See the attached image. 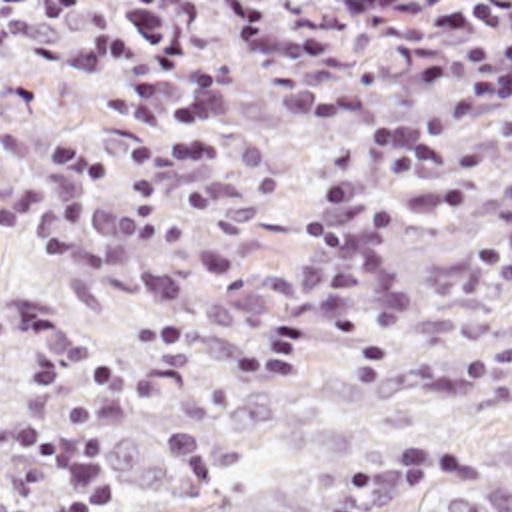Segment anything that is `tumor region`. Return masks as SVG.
<instances>
[{"label":"tumor region","instance_id":"e687c5a6","mask_svg":"<svg viewBox=\"0 0 512 512\" xmlns=\"http://www.w3.org/2000/svg\"><path fill=\"white\" fill-rule=\"evenodd\" d=\"M87 435L103 512H512V349L189 387H75L0 405ZM53 475L0 453V512Z\"/></svg>","mask_w":512,"mask_h":512}]
</instances>
